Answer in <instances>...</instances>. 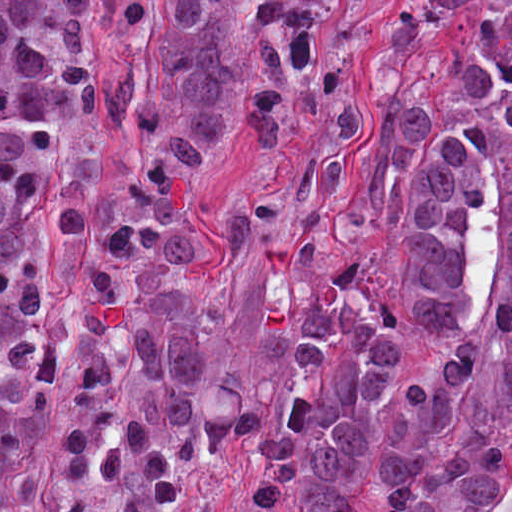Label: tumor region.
<instances>
[{
    "label": "tumor region",
    "instance_id": "1",
    "mask_svg": "<svg viewBox=\"0 0 512 512\" xmlns=\"http://www.w3.org/2000/svg\"><path fill=\"white\" fill-rule=\"evenodd\" d=\"M340 0H166L163 61L106 114L131 150L128 197L76 321L74 454L52 512H184L209 467L241 459L240 512H512V0H405L368 76L378 126L325 256L343 159L361 131L334 76ZM93 0H0V512H19L60 354L34 240L84 221L52 161L93 116L110 55ZM123 26L143 0H110ZM259 150L225 267L262 270L270 375L241 414L204 413L212 340L188 311L194 186L231 113ZM424 357L379 421L402 350Z\"/></svg>",
    "mask_w": 512,
    "mask_h": 512
}]
</instances>
